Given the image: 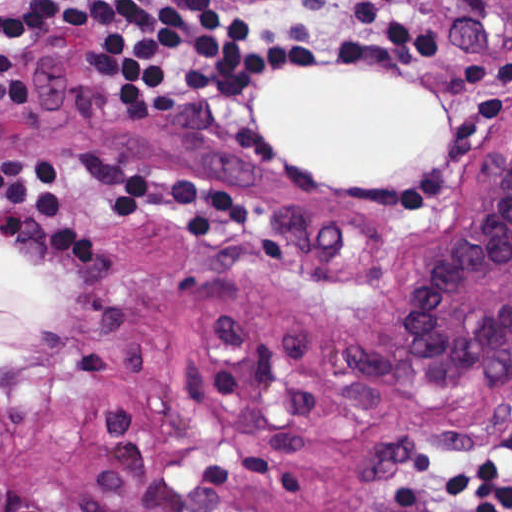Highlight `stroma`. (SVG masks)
Here are the masks:
<instances>
[{
  "label": "stroma",
  "instance_id": "obj_1",
  "mask_svg": "<svg viewBox=\"0 0 512 512\" xmlns=\"http://www.w3.org/2000/svg\"><path fill=\"white\" fill-rule=\"evenodd\" d=\"M447 144L400 182L325 184L256 134L273 79L127 113L101 56L1 61L0 512H386L512 419V342L421 377L445 233L512 147V0H433ZM1 243L60 309L1 382Z\"/></svg>",
  "mask_w": 512,
  "mask_h": 512
}]
</instances>
